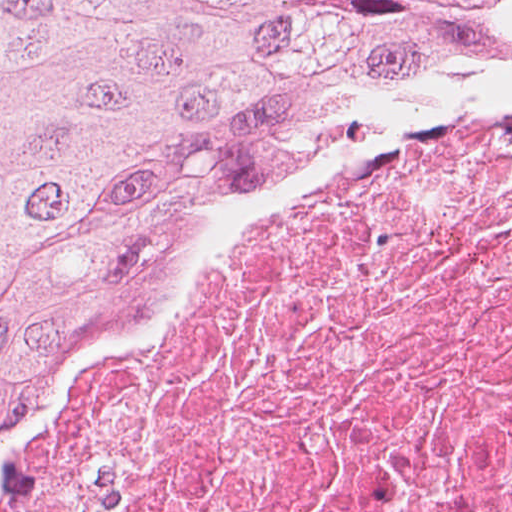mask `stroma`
<instances>
[{
    "instance_id": "obj_1",
    "label": "stroma",
    "mask_w": 512,
    "mask_h": 512,
    "mask_svg": "<svg viewBox=\"0 0 512 512\" xmlns=\"http://www.w3.org/2000/svg\"><path fill=\"white\" fill-rule=\"evenodd\" d=\"M512 90V53L419 50L375 63L287 113L178 228L106 275L79 318L52 333L0 391V462L14 428L45 385L141 296L160 271L271 206L309 177L360 160Z\"/></svg>"
}]
</instances>
